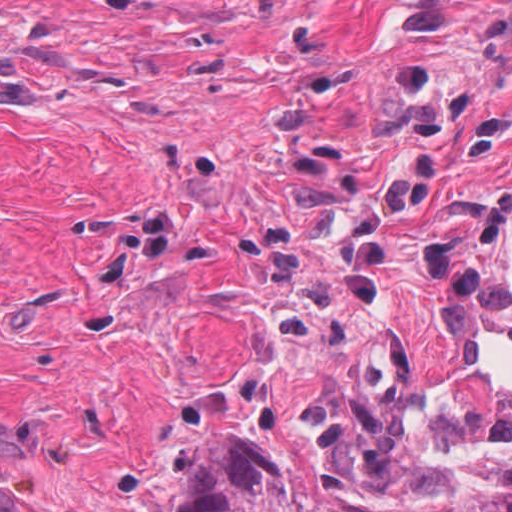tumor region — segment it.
Returning a JSON list of instances; mask_svg holds the SVG:
<instances>
[{"label": "tumor region", "mask_w": 512, "mask_h": 512, "mask_svg": "<svg viewBox=\"0 0 512 512\" xmlns=\"http://www.w3.org/2000/svg\"><path fill=\"white\" fill-rule=\"evenodd\" d=\"M175 512H512V479L468 482L438 499L371 502L236 432L229 405L177 435Z\"/></svg>", "instance_id": "1"}]
</instances>
